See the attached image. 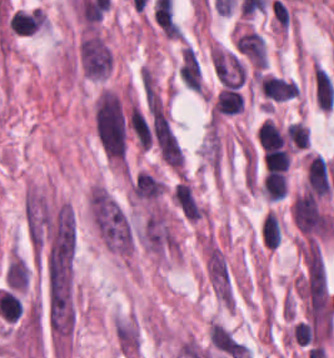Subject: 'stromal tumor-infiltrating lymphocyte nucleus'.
I'll return each instance as SVG.
<instances>
[{
  "mask_svg": "<svg viewBox=\"0 0 334 358\" xmlns=\"http://www.w3.org/2000/svg\"><path fill=\"white\" fill-rule=\"evenodd\" d=\"M257 80L268 99L282 101L298 94V84L293 79L276 74L260 73Z\"/></svg>",
  "mask_w": 334,
  "mask_h": 358,
  "instance_id": "bc302bb0",
  "label": "stromal tumor-infiltrating lymphocyte nucleus"
},
{
  "mask_svg": "<svg viewBox=\"0 0 334 358\" xmlns=\"http://www.w3.org/2000/svg\"><path fill=\"white\" fill-rule=\"evenodd\" d=\"M286 138L290 144L299 148H306L309 144V134L306 124L298 120H291L286 124Z\"/></svg>",
  "mask_w": 334,
  "mask_h": 358,
  "instance_id": "2a367800",
  "label": "stromal tumor-infiltrating lymphocyte nucleus"
},
{
  "mask_svg": "<svg viewBox=\"0 0 334 358\" xmlns=\"http://www.w3.org/2000/svg\"><path fill=\"white\" fill-rule=\"evenodd\" d=\"M261 190L267 200L274 202L284 198L287 191L284 172L267 171L262 181Z\"/></svg>",
  "mask_w": 334,
  "mask_h": 358,
  "instance_id": "3290ff9b",
  "label": "stromal tumor-infiltrating lymphocyte nucleus"
},
{
  "mask_svg": "<svg viewBox=\"0 0 334 358\" xmlns=\"http://www.w3.org/2000/svg\"><path fill=\"white\" fill-rule=\"evenodd\" d=\"M263 163L270 170L286 172L289 163L288 148H268L263 154Z\"/></svg>",
  "mask_w": 334,
  "mask_h": 358,
  "instance_id": "4f13568d",
  "label": "stromal tumor-infiltrating lymphocyte nucleus"
},
{
  "mask_svg": "<svg viewBox=\"0 0 334 358\" xmlns=\"http://www.w3.org/2000/svg\"><path fill=\"white\" fill-rule=\"evenodd\" d=\"M243 108V98L237 87L226 86L220 90L213 110L234 114Z\"/></svg>",
  "mask_w": 334,
  "mask_h": 358,
  "instance_id": "abfb95fc",
  "label": "stromal tumor-infiltrating lymphocyte nucleus"
},
{
  "mask_svg": "<svg viewBox=\"0 0 334 358\" xmlns=\"http://www.w3.org/2000/svg\"><path fill=\"white\" fill-rule=\"evenodd\" d=\"M262 243L270 248L279 245L278 217L267 212L261 223Z\"/></svg>",
  "mask_w": 334,
  "mask_h": 358,
  "instance_id": "f3e2335f",
  "label": "stromal tumor-infiltrating lymphocyte nucleus"
},
{
  "mask_svg": "<svg viewBox=\"0 0 334 358\" xmlns=\"http://www.w3.org/2000/svg\"><path fill=\"white\" fill-rule=\"evenodd\" d=\"M312 78L316 106L331 110L334 104V85L325 71L313 63Z\"/></svg>",
  "mask_w": 334,
  "mask_h": 358,
  "instance_id": "52c7bb5b",
  "label": "stromal tumor-infiltrating lymphocyte nucleus"
},
{
  "mask_svg": "<svg viewBox=\"0 0 334 358\" xmlns=\"http://www.w3.org/2000/svg\"><path fill=\"white\" fill-rule=\"evenodd\" d=\"M257 138L263 149H272L282 146L284 134L271 119H263L256 130Z\"/></svg>",
  "mask_w": 334,
  "mask_h": 358,
  "instance_id": "9ea309e8",
  "label": "stromal tumor-infiltrating lymphocyte nucleus"
}]
</instances>
